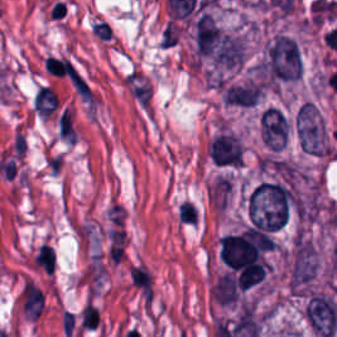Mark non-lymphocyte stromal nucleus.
Returning <instances> with one entry per match:
<instances>
[{
	"mask_svg": "<svg viewBox=\"0 0 337 337\" xmlns=\"http://www.w3.org/2000/svg\"><path fill=\"white\" fill-rule=\"evenodd\" d=\"M126 276L140 300L149 304L155 292L152 273L141 262H134L127 268Z\"/></svg>",
	"mask_w": 337,
	"mask_h": 337,
	"instance_id": "obj_1",
	"label": "non-lymphocyte stromal nucleus"
},
{
	"mask_svg": "<svg viewBox=\"0 0 337 337\" xmlns=\"http://www.w3.org/2000/svg\"><path fill=\"white\" fill-rule=\"evenodd\" d=\"M21 304L30 317H36L43 309V291L34 283L24 282L21 294Z\"/></svg>",
	"mask_w": 337,
	"mask_h": 337,
	"instance_id": "obj_2",
	"label": "non-lymphocyte stromal nucleus"
}]
</instances>
